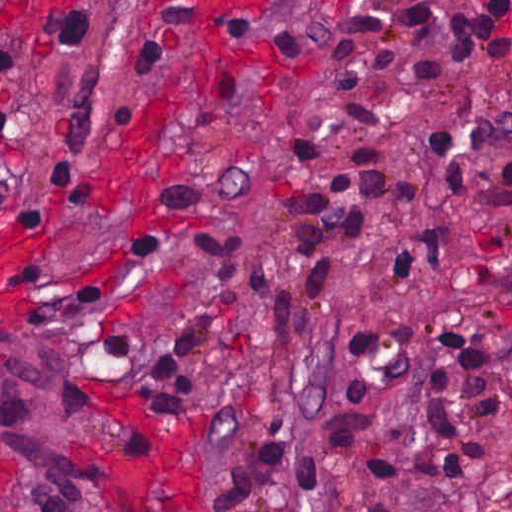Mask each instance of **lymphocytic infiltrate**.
<instances>
[{
	"mask_svg": "<svg viewBox=\"0 0 512 512\" xmlns=\"http://www.w3.org/2000/svg\"><path fill=\"white\" fill-rule=\"evenodd\" d=\"M492 48L493 40L459 0H449L441 10H418L346 31L302 133L298 180L323 158L310 130L315 118L361 131L380 130L377 113L323 99L327 94L356 86L401 56H417L405 77L421 81L461 62H486ZM91 52L92 39L79 18L56 23L51 49L21 110L0 104V135L8 141H73L92 106ZM431 141L437 157L433 205L473 210L490 223H512V164L491 166L483 180L471 183L462 167L459 134L442 129L431 134ZM470 141L476 153L512 141V115L476 122ZM381 198L382 165L371 150L350 158L313 193L292 197L281 221L294 229L307 294L328 290L348 246ZM193 237L211 274L194 324L186 335L147 354L141 366L153 403L176 416L196 407L192 374L206 348L245 317L239 236L200 228ZM415 267L441 285L451 269V240L429 216L403 259L377 276L389 290L399 291ZM261 292L272 326L298 330L316 317L298 314L291 298L276 289L261 285ZM332 315L322 313L317 321ZM355 329L364 347L384 343L377 329L358 324ZM484 337L478 326L449 320L436 345ZM496 426L512 429V351L411 360L365 374L322 415L312 433L306 454V512H397L416 487L480 475L484 438Z\"/></svg>",
	"mask_w": 512,
	"mask_h": 512,
	"instance_id": "1",
	"label": "lymphocytic infiltrate"
}]
</instances>
